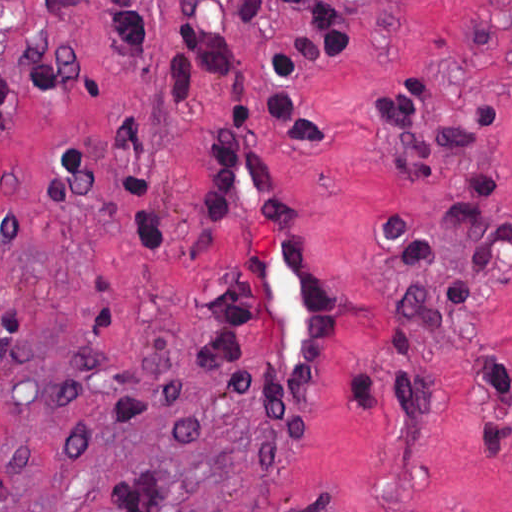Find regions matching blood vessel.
I'll return each mask as SVG.
<instances>
[{
  "mask_svg": "<svg viewBox=\"0 0 512 512\" xmlns=\"http://www.w3.org/2000/svg\"><path fill=\"white\" fill-rule=\"evenodd\" d=\"M234 194L262 263L266 363L282 397L304 401L316 394L326 363L323 273L277 210L258 148L241 154Z\"/></svg>",
  "mask_w": 512,
  "mask_h": 512,
  "instance_id": "blood-vessel-1",
  "label": "blood vessel"
}]
</instances>
